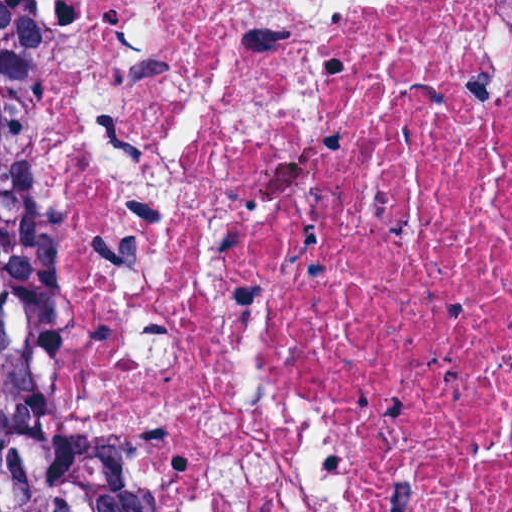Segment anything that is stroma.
I'll list each match as a JSON object with an SVG mask.
<instances>
[{
    "label": "stroma",
    "instance_id": "obj_1",
    "mask_svg": "<svg viewBox=\"0 0 512 512\" xmlns=\"http://www.w3.org/2000/svg\"><path fill=\"white\" fill-rule=\"evenodd\" d=\"M12 125V86L8 101V106L6 110L4 124L0 131V149L1 146L7 136V133ZM0 315L4 318V320L9 324V326L16 333V321L18 312L14 309V307L8 303L4 298L0 296Z\"/></svg>",
    "mask_w": 512,
    "mask_h": 512
}]
</instances>
